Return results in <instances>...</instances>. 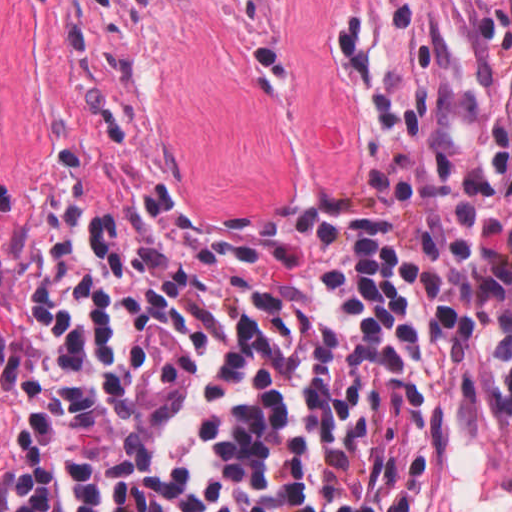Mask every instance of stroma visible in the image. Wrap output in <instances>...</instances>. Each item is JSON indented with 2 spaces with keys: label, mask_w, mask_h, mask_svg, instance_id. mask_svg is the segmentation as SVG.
<instances>
[{
  "label": "stroma",
  "mask_w": 512,
  "mask_h": 512,
  "mask_svg": "<svg viewBox=\"0 0 512 512\" xmlns=\"http://www.w3.org/2000/svg\"><path fill=\"white\" fill-rule=\"evenodd\" d=\"M400 146L512 249V124L440 0H0V492L57 166L296 218L374 210ZM439 512H512V296L459 342Z\"/></svg>",
  "instance_id": "obj_1"
}]
</instances>
